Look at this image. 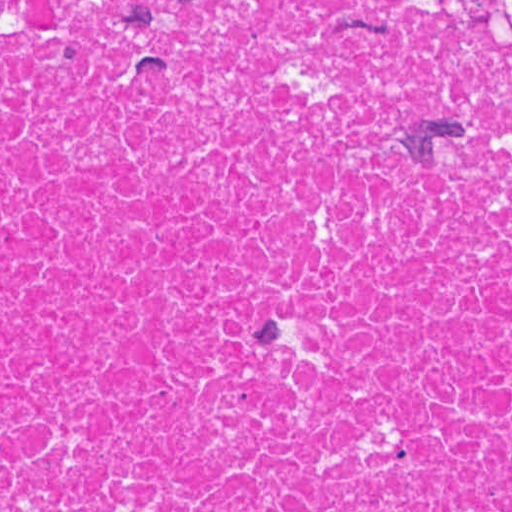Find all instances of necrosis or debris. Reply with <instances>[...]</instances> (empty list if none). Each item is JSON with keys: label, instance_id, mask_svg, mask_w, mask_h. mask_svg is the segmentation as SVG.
Segmentation results:
<instances>
[{"label": "necrosis or debris", "instance_id": "4bbe7bcc", "mask_svg": "<svg viewBox=\"0 0 512 512\" xmlns=\"http://www.w3.org/2000/svg\"><path fill=\"white\" fill-rule=\"evenodd\" d=\"M507 11L0 0V512H512Z\"/></svg>", "mask_w": 512, "mask_h": 512}]
</instances>
